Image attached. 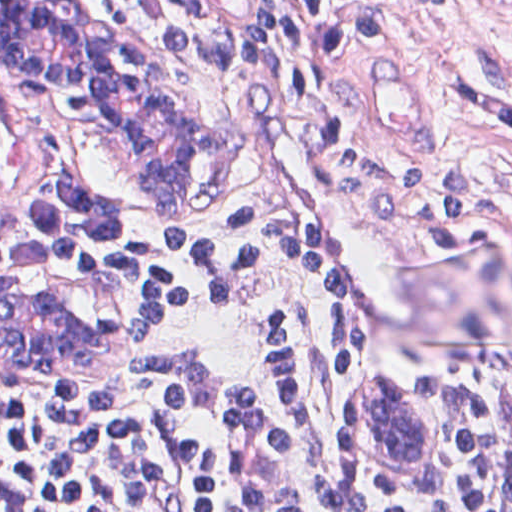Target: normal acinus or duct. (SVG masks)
I'll list each match as a JSON object with an SVG mask.
<instances>
[{"label":"normal acinus or duct","instance_id":"30e58d81","mask_svg":"<svg viewBox=\"0 0 512 512\" xmlns=\"http://www.w3.org/2000/svg\"><path fill=\"white\" fill-rule=\"evenodd\" d=\"M77 11L65 0H0V82L82 142L124 147L136 184L158 198L181 199L199 170V143L178 100L139 50L80 25ZM24 284L27 290L0 287V349L38 358L88 351L86 330L30 277ZM391 387H362L347 411L361 461L379 471L404 465L418 446L415 424Z\"/></svg>","mask_w":512,"mask_h":512}]
</instances>
